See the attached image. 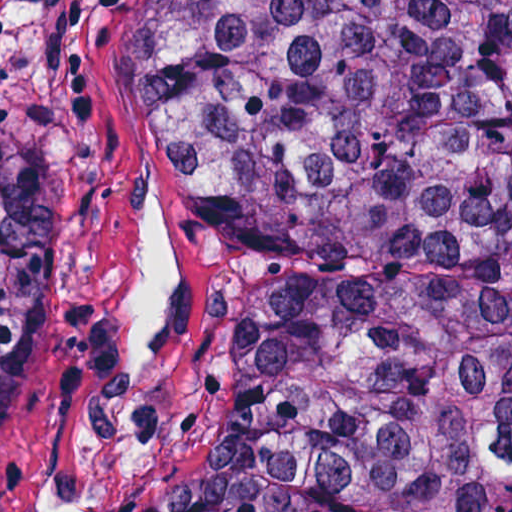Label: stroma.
I'll use <instances>...</instances> for the list:
<instances>
[{
	"mask_svg": "<svg viewBox=\"0 0 512 512\" xmlns=\"http://www.w3.org/2000/svg\"><path fill=\"white\" fill-rule=\"evenodd\" d=\"M139 0H38V267L0 512H131L204 439L235 220L184 201L122 109Z\"/></svg>",
	"mask_w": 512,
	"mask_h": 512,
	"instance_id": "obj_1",
	"label": "stroma"
}]
</instances>
